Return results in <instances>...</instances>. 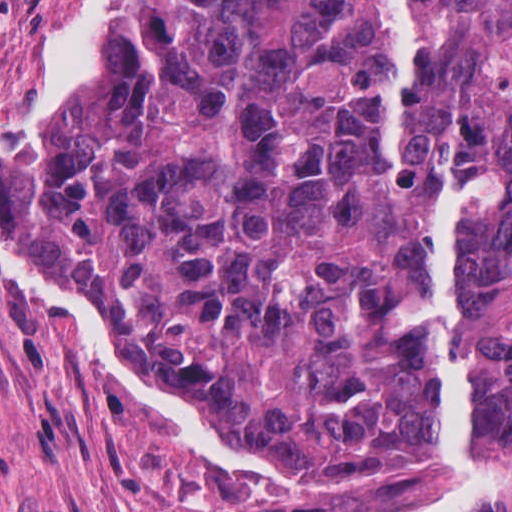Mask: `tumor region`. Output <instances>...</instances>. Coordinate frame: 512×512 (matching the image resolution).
<instances>
[{"label":"tumor region","instance_id":"obj_1","mask_svg":"<svg viewBox=\"0 0 512 512\" xmlns=\"http://www.w3.org/2000/svg\"><path fill=\"white\" fill-rule=\"evenodd\" d=\"M400 178L489 187L458 237L467 446L511 474L512 0H408ZM392 92L374 0H108L74 74L0 137V244L165 411L288 479L425 469L443 401L386 324L426 216L375 192Z\"/></svg>","mask_w":512,"mask_h":512}]
</instances>
